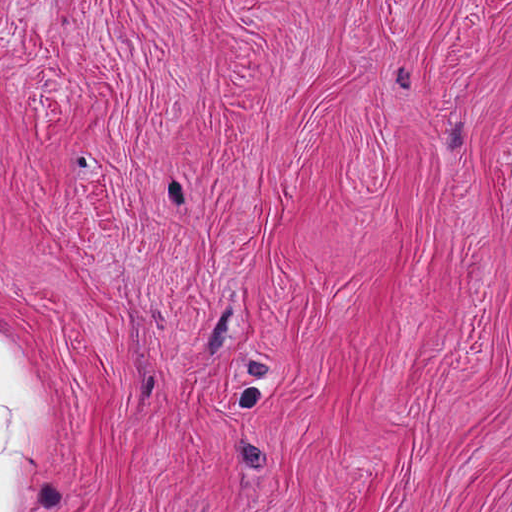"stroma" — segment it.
Instances as JSON below:
<instances>
[{"label": "stroma", "instance_id": "stroma-1", "mask_svg": "<svg viewBox=\"0 0 512 512\" xmlns=\"http://www.w3.org/2000/svg\"><path fill=\"white\" fill-rule=\"evenodd\" d=\"M0 339L31 512H512V0H0Z\"/></svg>", "mask_w": 512, "mask_h": 512}]
</instances>
